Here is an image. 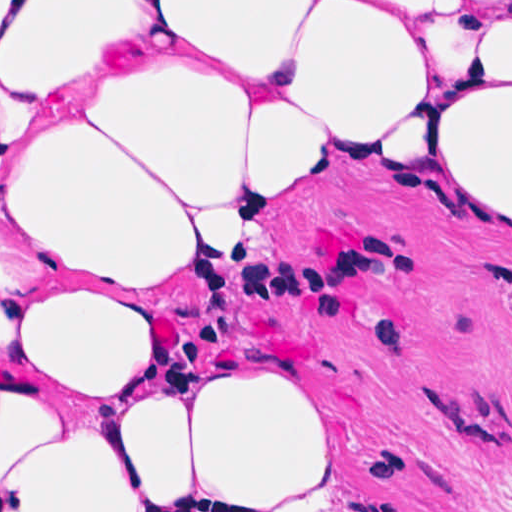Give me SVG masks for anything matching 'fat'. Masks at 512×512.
Returning a JSON list of instances; mask_svg holds the SVG:
<instances>
[{
	"label": "fat",
	"mask_w": 512,
	"mask_h": 512,
	"mask_svg": "<svg viewBox=\"0 0 512 512\" xmlns=\"http://www.w3.org/2000/svg\"><path fill=\"white\" fill-rule=\"evenodd\" d=\"M414 124L512 229V2L360 83L323 1H0V353L109 393L143 360L146 291L230 258L242 218L332 151ZM331 467L314 396L282 374L100 417L0 382V512L243 508Z\"/></svg>",
	"instance_id": "1"
}]
</instances>
